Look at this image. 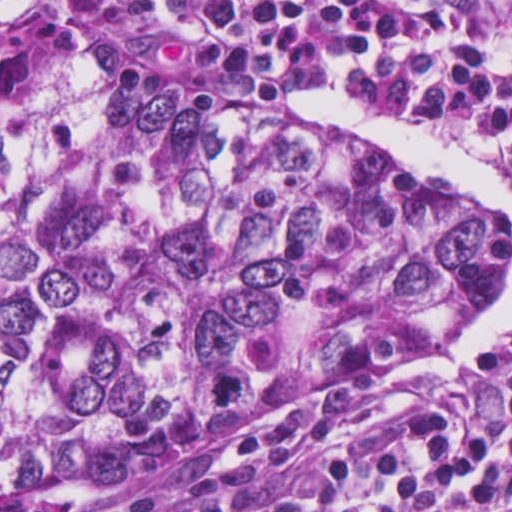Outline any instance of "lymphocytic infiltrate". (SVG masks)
Listing matches in <instances>:
<instances>
[{
  "mask_svg": "<svg viewBox=\"0 0 512 512\" xmlns=\"http://www.w3.org/2000/svg\"><path fill=\"white\" fill-rule=\"evenodd\" d=\"M156 60L227 92L350 90L512 171V0H67ZM454 400L387 412L345 438L331 415L250 431L241 458L107 512H512V339Z\"/></svg>",
  "mask_w": 512,
  "mask_h": 512,
  "instance_id": "lymphocytic-infiltrate-1",
  "label": "lymphocytic infiltrate"
}]
</instances>
